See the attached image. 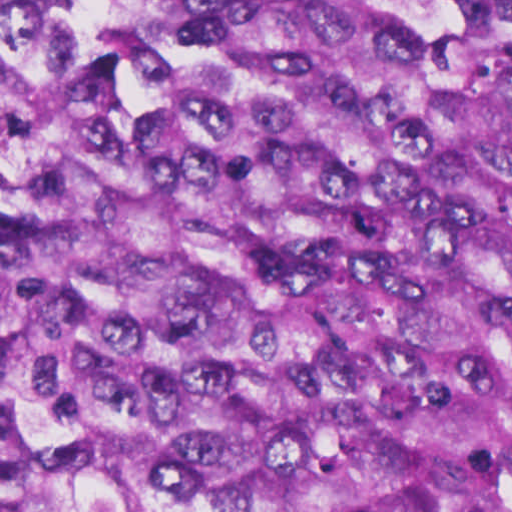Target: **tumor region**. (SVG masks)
I'll return each mask as SVG.
<instances>
[{
    "mask_svg": "<svg viewBox=\"0 0 512 512\" xmlns=\"http://www.w3.org/2000/svg\"><path fill=\"white\" fill-rule=\"evenodd\" d=\"M0 512H512V0H0Z\"/></svg>",
    "mask_w": 512,
    "mask_h": 512,
    "instance_id": "1",
    "label": "tumor region"
}]
</instances>
